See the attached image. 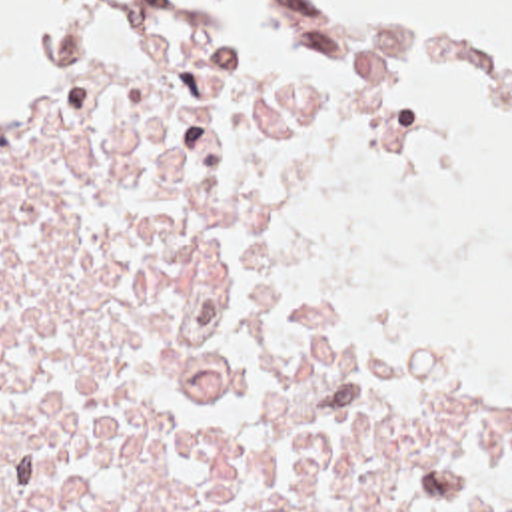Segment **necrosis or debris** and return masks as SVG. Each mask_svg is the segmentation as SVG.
I'll return each mask as SVG.
<instances>
[{
  "label": "necrosis or debris",
  "mask_w": 512,
  "mask_h": 512,
  "mask_svg": "<svg viewBox=\"0 0 512 512\" xmlns=\"http://www.w3.org/2000/svg\"><path fill=\"white\" fill-rule=\"evenodd\" d=\"M446 179L390 71L105 7L0 91V512H512V381L420 363L330 261L344 207Z\"/></svg>",
  "instance_id": "obj_1"
}]
</instances>
